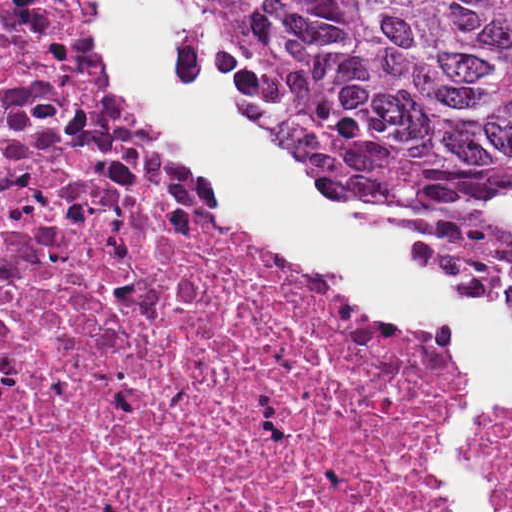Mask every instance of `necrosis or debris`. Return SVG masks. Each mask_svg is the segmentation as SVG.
Returning a JSON list of instances; mask_svg holds the SVG:
<instances>
[{
    "label": "necrosis or debris",
    "instance_id": "1",
    "mask_svg": "<svg viewBox=\"0 0 512 512\" xmlns=\"http://www.w3.org/2000/svg\"><path fill=\"white\" fill-rule=\"evenodd\" d=\"M0 19L1 512H450L473 350L157 143L97 0ZM484 478L512 512V441Z\"/></svg>",
    "mask_w": 512,
    "mask_h": 512
}]
</instances>
